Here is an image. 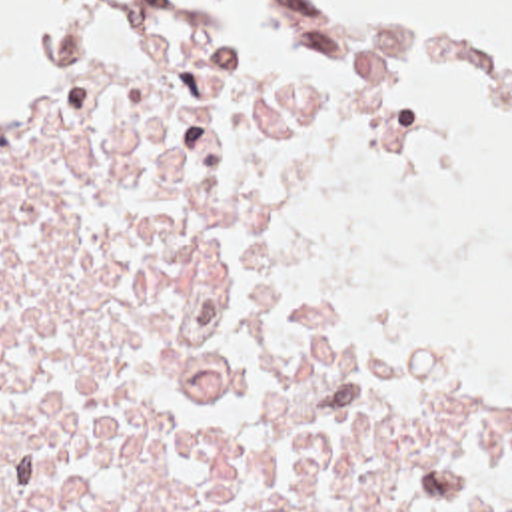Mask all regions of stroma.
Wrapping results in <instances>:
<instances>
[{
  "mask_svg": "<svg viewBox=\"0 0 512 512\" xmlns=\"http://www.w3.org/2000/svg\"><path fill=\"white\" fill-rule=\"evenodd\" d=\"M105 7H185V9H197V11H205L209 21L213 23L211 19V13H209V7H207V1L205 0H99L91 17L83 23H79L77 27L65 31L61 37H57L55 41L51 43H45L39 47V51L27 59H23L21 67L3 83L0 87L5 89L7 85H11L13 81L25 77V75H31L35 71H41L45 67H51L59 61H63L65 57H69L71 53H75L77 49L83 47L93 23L97 21V17L103 13ZM287 11L295 13L312 33L310 29L309 19L305 15V9L301 5L299 0H287ZM215 31L221 35V39L229 45V49L235 53L237 61L241 63L243 71H249V73H261V75H336L340 71H346L358 63H364V65H372V67H378V69H386L390 71L396 79H400L416 97L418 101L430 111L432 119L436 121L442 137H444V143L448 147V179L444 181V185L436 191V195L432 199H426V201H416V203H364V205H352V207H344L340 219L336 221L332 233H330V261H332V271H334V277L354 295L358 297L366 307H370L374 313L382 315L362 293L360 289L354 285V281L350 279L348 271H346V251H344V241H342V235L352 231V229H368V227H374V225H380L384 221H390V219H396L404 213H410V211H416L440 197H446L454 191H458L462 185H464V167L458 159V143H456V135L452 133L442 109L438 103H434L424 89L412 85L408 81V77L394 65L390 63L386 57L370 51V49H364L360 45H354L346 51H342L340 55L324 61H259V59H251L247 55H243L239 49L233 47L229 35L219 27L215 25ZM384 317V315H382ZM400 329L406 333V337L410 339L414 351H416V357L420 363H426V365H440V367H454V369H470V371H484V373H494V375H500L508 381H512V367L510 365H504V363H496V361H452L450 357H446L444 353L440 355L438 351H434L424 339H420L416 333H412L408 327L400 325Z\"/></svg>",
  "mask_w": 512,
  "mask_h": 512,
  "instance_id": "obj_1",
  "label": "stroma"
}]
</instances>
